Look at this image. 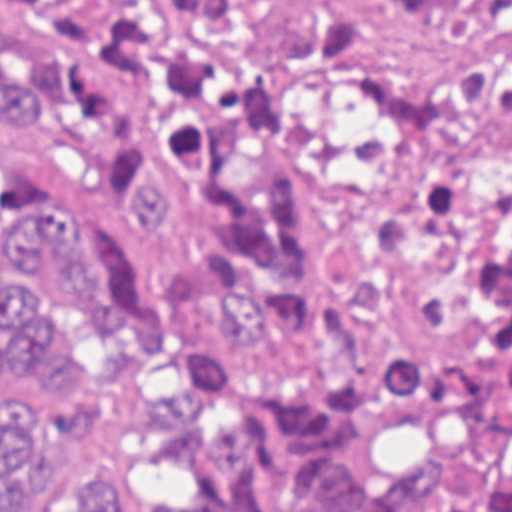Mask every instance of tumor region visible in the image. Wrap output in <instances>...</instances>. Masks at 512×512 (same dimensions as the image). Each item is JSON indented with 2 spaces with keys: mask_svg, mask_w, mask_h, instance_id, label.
I'll return each instance as SVG.
<instances>
[{
  "mask_svg": "<svg viewBox=\"0 0 512 512\" xmlns=\"http://www.w3.org/2000/svg\"><path fill=\"white\" fill-rule=\"evenodd\" d=\"M178 1H0V143L52 132L117 191L161 149L153 97ZM126 231L177 267L141 301L138 260L0 157V512L40 444L95 422L111 362L58 336L117 331L172 372L138 512H512V132L467 135L374 223L340 290L282 137L230 105L181 109ZM122 476L71 474L42 512H115Z\"/></svg>",
  "mask_w": 512,
  "mask_h": 512,
  "instance_id": "tumor-region-1",
  "label": "tumor region"
}]
</instances>
